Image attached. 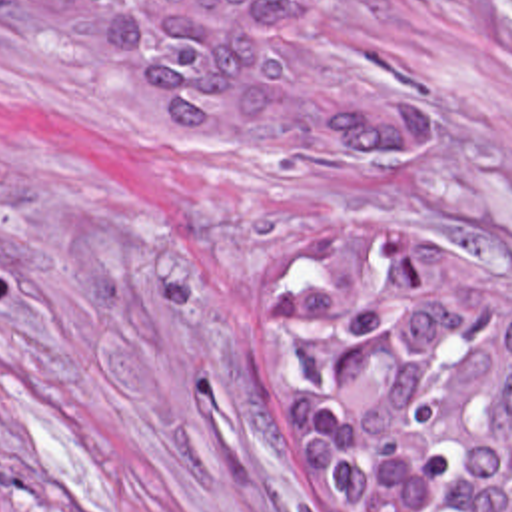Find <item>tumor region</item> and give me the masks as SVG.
<instances>
[{"label":"tumor region","instance_id":"obj_1","mask_svg":"<svg viewBox=\"0 0 512 512\" xmlns=\"http://www.w3.org/2000/svg\"><path fill=\"white\" fill-rule=\"evenodd\" d=\"M173 157L243 181H387L430 99L315 35V0H45ZM257 357L301 430L315 512H512V265L337 233L257 295Z\"/></svg>","mask_w":512,"mask_h":512}]
</instances>
